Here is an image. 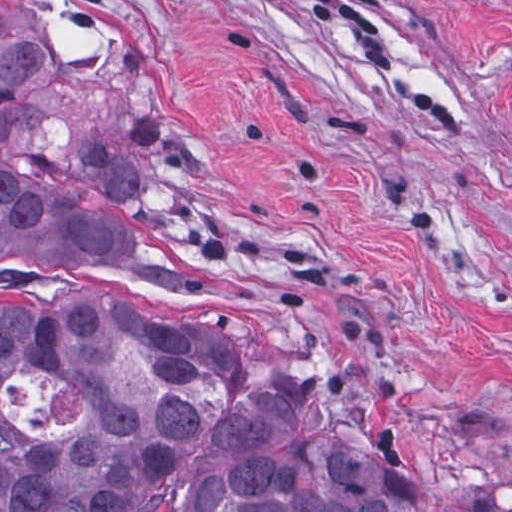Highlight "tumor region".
I'll use <instances>...</instances> for the list:
<instances>
[{"instance_id":"obj_1","label":"tumor region","mask_w":512,"mask_h":512,"mask_svg":"<svg viewBox=\"0 0 512 512\" xmlns=\"http://www.w3.org/2000/svg\"><path fill=\"white\" fill-rule=\"evenodd\" d=\"M42 43L0 9V247L76 277L193 287L230 267L108 202L141 174L93 141L63 166L11 153ZM0 289V385L35 372L80 394L59 433L0 410V512H419L293 441L218 331Z\"/></svg>"}]
</instances>
